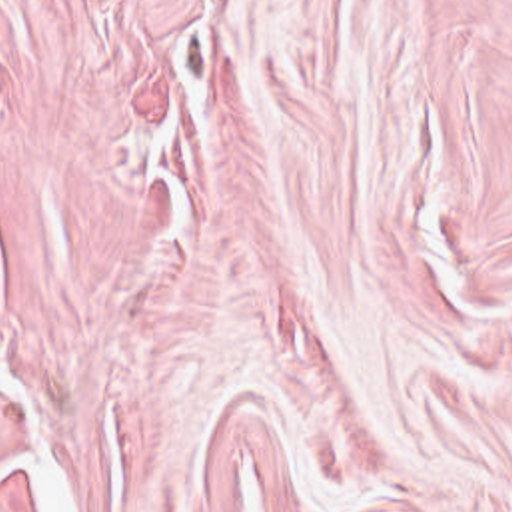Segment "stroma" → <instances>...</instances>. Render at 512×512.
Instances as JSON below:
<instances>
[{
    "instance_id": "obj_1",
    "label": "stroma",
    "mask_w": 512,
    "mask_h": 512,
    "mask_svg": "<svg viewBox=\"0 0 512 512\" xmlns=\"http://www.w3.org/2000/svg\"><path fill=\"white\" fill-rule=\"evenodd\" d=\"M512 512V0H0V512Z\"/></svg>"
}]
</instances>
